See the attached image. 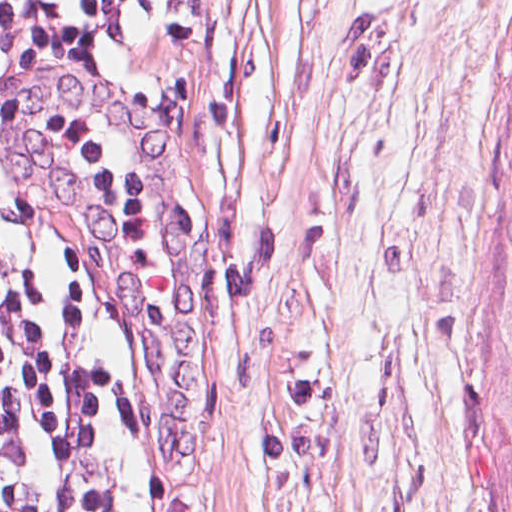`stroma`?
Listing matches in <instances>:
<instances>
[{
  "mask_svg": "<svg viewBox=\"0 0 512 512\" xmlns=\"http://www.w3.org/2000/svg\"><path fill=\"white\" fill-rule=\"evenodd\" d=\"M512 0L0 22V257L58 512H494Z\"/></svg>",
  "mask_w": 512,
  "mask_h": 512,
  "instance_id": "stroma-1",
  "label": "stroma"
}]
</instances>
